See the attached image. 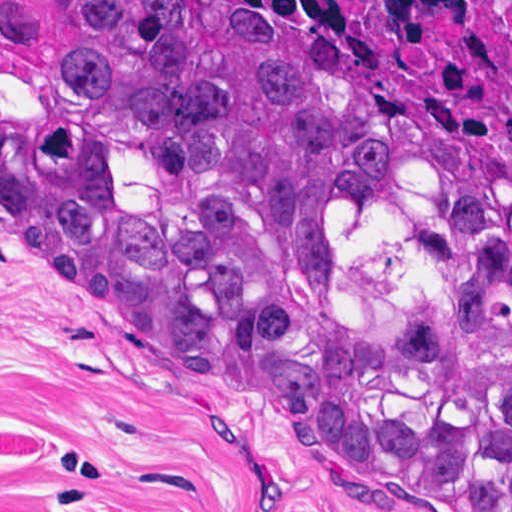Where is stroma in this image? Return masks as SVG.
Returning a JSON list of instances; mask_svg holds the SVG:
<instances>
[{
    "label": "stroma",
    "mask_w": 512,
    "mask_h": 512,
    "mask_svg": "<svg viewBox=\"0 0 512 512\" xmlns=\"http://www.w3.org/2000/svg\"><path fill=\"white\" fill-rule=\"evenodd\" d=\"M0 512H459L0 242Z\"/></svg>",
    "instance_id": "1"
}]
</instances>
